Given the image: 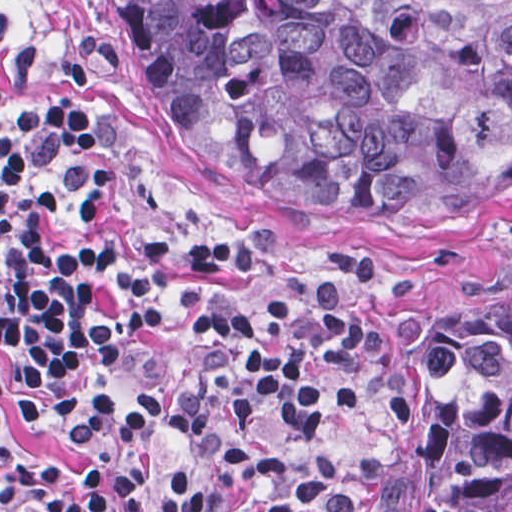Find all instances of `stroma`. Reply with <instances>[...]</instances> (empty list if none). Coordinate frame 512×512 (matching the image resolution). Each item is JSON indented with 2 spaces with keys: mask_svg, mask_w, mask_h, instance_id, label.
I'll return each mask as SVG.
<instances>
[{
  "mask_svg": "<svg viewBox=\"0 0 512 512\" xmlns=\"http://www.w3.org/2000/svg\"><path fill=\"white\" fill-rule=\"evenodd\" d=\"M84 31L95 70L77 89L62 62ZM35 47V68L19 91L1 93V59ZM43 97L74 103L91 137L105 140L119 184L150 215H223L240 223L282 227L288 252L247 295L271 302L325 287L373 290V332L349 415L333 452L348 500L359 512L363 487L398 454L380 394L383 320L407 305L443 300L467 287L512 279V211L448 228H289L237 206L197 175L153 123L133 37L118 0H0V512L1 440L25 460L46 458L87 476L80 445L62 432L23 422L18 403L34 390L1 369V127ZM187 435L167 425L153 439L150 473L125 512H156L186 458Z\"/></svg>",
  "mask_w": 512,
  "mask_h": 512,
  "instance_id": "stroma-1",
  "label": "stroma"
}]
</instances>
